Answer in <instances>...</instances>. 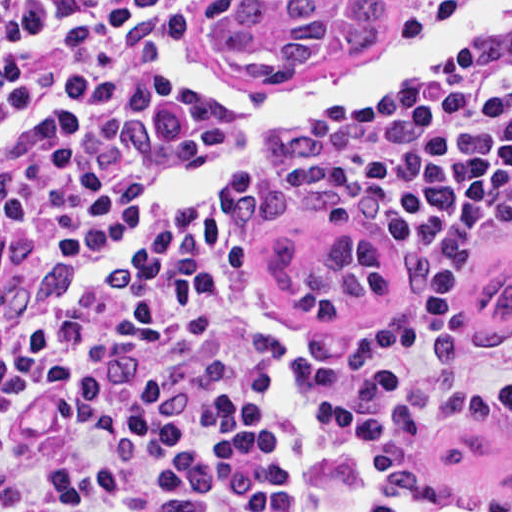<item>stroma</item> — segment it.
<instances>
[{"instance_id":"1","label":"stroma","mask_w":512,"mask_h":512,"mask_svg":"<svg viewBox=\"0 0 512 512\" xmlns=\"http://www.w3.org/2000/svg\"><path fill=\"white\" fill-rule=\"evenodd\" d=\"M222 0H198L185 21V39L196 57L259 97L288 94L309 82L355 70L397 38L417 29L437 12L463 0H382L378 38L362 53H338L294 79H247L215 66L201 43L208 12ZM512 55V18L445 76L333 115L295 120L278 164L254 180L236 204L251 253L252 275L278 314L288 336L307 355H327L392 336L410 316L422 276L411 240L392 230L351 225L310 209L285 193V178L301 149L315 136L365 112L418 90L444 84L495 65ZM233 137L220 125L177 170L136 203L113 227L107 240L159 215V200L180 178L208 167ZM178 215V214H176ZM70 264L53 269L52 284ZM512 414L467 429L441 433L422 450Z\"/></svg>"}]
</instances>
